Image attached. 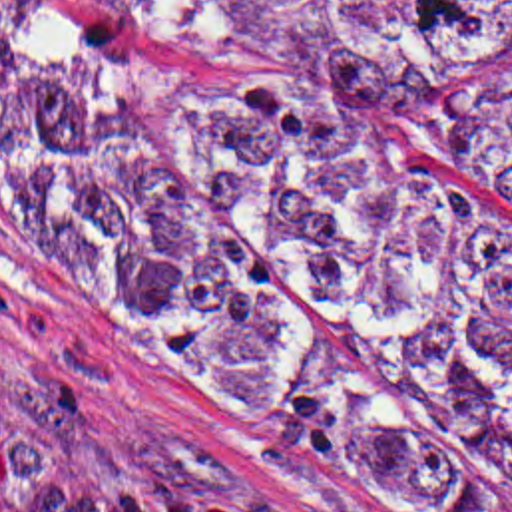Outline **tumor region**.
Masks as SVG:
<instances>
[{
	"instance_id": "obj_1",
	"label": "tumor region",
	"mask_w": 512,
	"mask_h": 512,
	"mask_svg": "<svg viewBox=\"0 0 512 512\" xmlns=\"http://www.w3.org/2000/svg\"><path fill=\"white\" fill-rule=\"evenodd\" d=\"M225 67L0 87V160L141 340L380 485L512 505V240L384 142L512 196V0H126Z\"/></svg>"
}]
</instances>
